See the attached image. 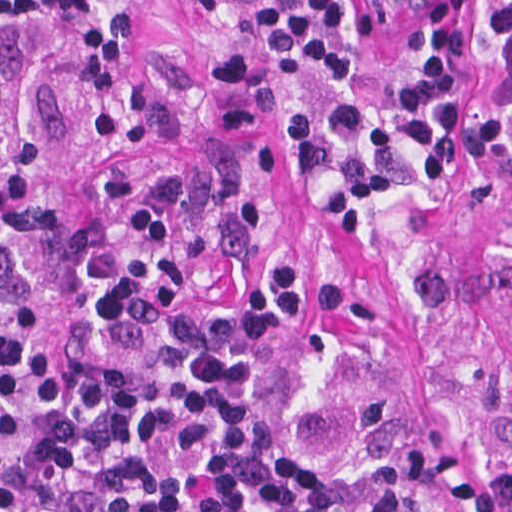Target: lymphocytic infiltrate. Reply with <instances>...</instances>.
Wrapping results in <instances>:
<instances>
[{
	"instance_id": "f902f5d3",
	"label": "lymphocytic infiltrate",
	"mask_w": 512,
	"mask_h": 512,
	"mask_svg": "<svg viewBox=\"0 0 512 512\" xmlns=\"http://www.w3.org/2000/svg\"><path fill=\"white\" fill-rule=\"evenodd\" d=\"M183 13L228 17L323 77L359 60L344 0H165ZM487 35L512 79V0H485ZM79 44V75L110 101L125 55V12L105 0H50ZM464 0H427L422 46L404 92L424 179L450 176L464 117ZM0 8L41 22L39 0ZM296 172L348 165L317 196L330 234L361 230L392 187L370 158V119L340 101L321 123L304 102L284 114ZM39 182V145L0 92V244L20 228ZM127 261L93 301L99 318L137 310L172 251V222L144 200L126 220ZM313 318L310 267L277 260L251 298L184 301L170 343L152 351H51L0 312V512H444L360 467L332 463L260 398V366Z\"/></svg>"
}]
</instances>
